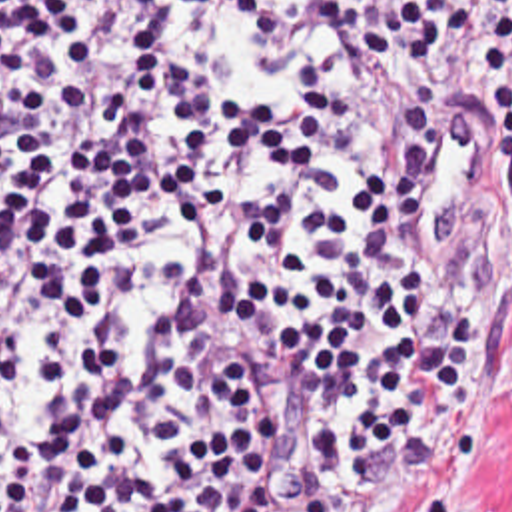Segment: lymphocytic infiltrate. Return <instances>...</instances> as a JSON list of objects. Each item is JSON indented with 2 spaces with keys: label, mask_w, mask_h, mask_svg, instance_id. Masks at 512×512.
Returning <instances> with one entry per match:
<instances>
[{
  "label": "lymphocytic infiltrate",
  "mask_w": 512,
  "mask_h": 512,
  "mask_svg": "<svg viewBox=\"0 0 512 512\" xmlns=\"http://www.w3.org/2000/svg\"><path fill=\"white\" fill-rule=\"evenodd\" d=\"M452 76L512 192V0H0V512L432 481L480 400Z\"/></svg>",
  "instance_id": "obj_1"
}]
</instances>
